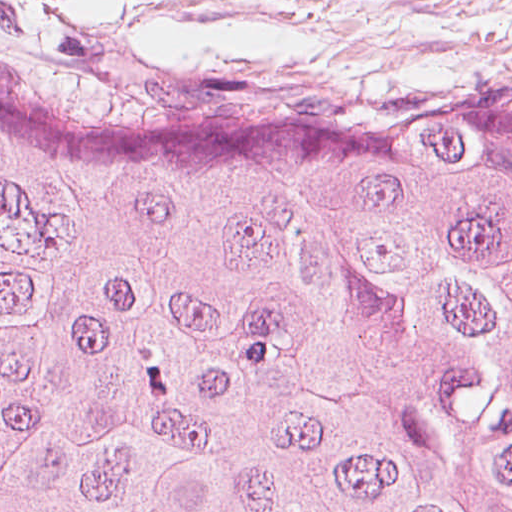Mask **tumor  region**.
Instances as JSON below:
<instances>
[{"label": "tumor region", "mask_w": 512, "mask_h": 512, "mask_svg": "<svg viewBox=\"0 0 512 512\" xmlns=\"http://www.w3.org/2000/svg\"><path fill=\"white\" fill-rule=\"evenodd\" d=\"M0 512H512V110L0 74Z\"/></svg>", "instance_id": "e687c5a6"}]
</instances>
